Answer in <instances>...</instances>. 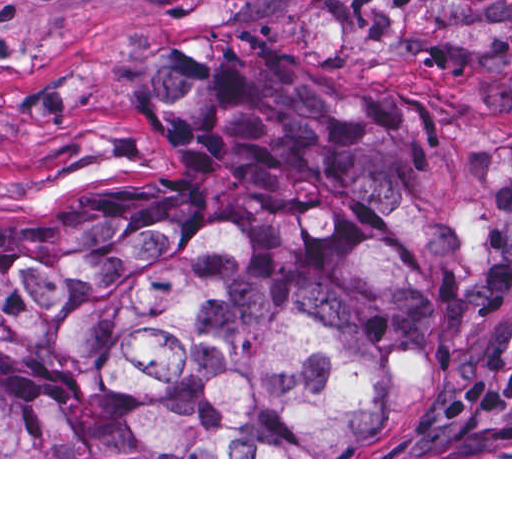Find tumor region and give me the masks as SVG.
<instances>
[{
	"label": "tumor region",
	"mask_w": 512,
	"mask_h": 512,
	"mask_svg": "<svg viewBox=\"0 0 512 512\" xmlns=\"http://www.w3.org/2000/svg\"><path fill=\"white\" fill-rule=\"evenodd\" d=\"M175 161L1 209V457H340L512 260V118L307 83L239 33L143 48ZM382 457H512V322Z\"/></svg>",
	"instance_id": "obj_1"
}]
</instances>
